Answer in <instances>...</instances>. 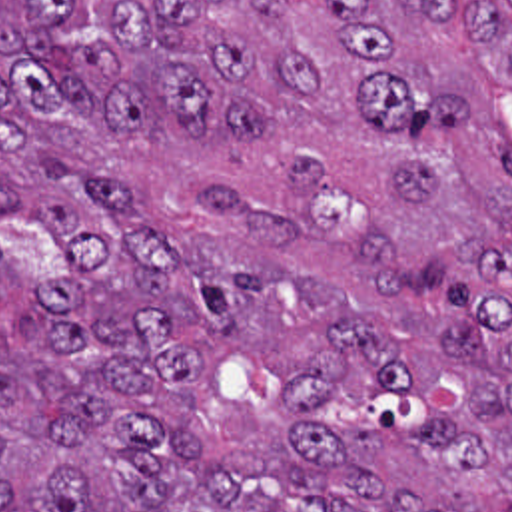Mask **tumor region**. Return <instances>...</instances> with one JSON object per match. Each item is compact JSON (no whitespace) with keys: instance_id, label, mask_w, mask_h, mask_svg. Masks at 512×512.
Segmentation results:
<instances>
[{"instance_id":"tumor-region-1","label":"tumor region","mask_w":512,"mask_h":512,"mask_svg":"<svg viewBox=\"0 0 512 512\" xmlns=\"http://www.w3.org/2000/svg\"><path fill=\"white\" fill-rule=\"evenodd\" d=\"M512 20L0 0V512H512Z\"/></svg>"}]
</instances>
